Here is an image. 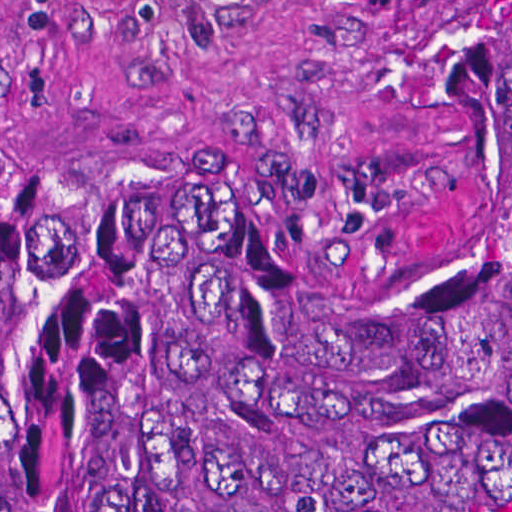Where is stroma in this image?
I'll return each mask as SVG.
<instances>
[{
  "instance_id": "35a3bbf8",
  "label": "stroma",
  "mask_w": 512,
  "mask_h": 512,
  "mask_svg": "<svg viewBox=\"0 0 512 512\" xmlns=\"http://www.w3.org/2000/svg\"><path fill=\"white\" fill-rule=\"evenodd\" d=\"M0 176L267 188L434 279L464 215L439 0H0Z\"/></svg>"
}]
</instances>
